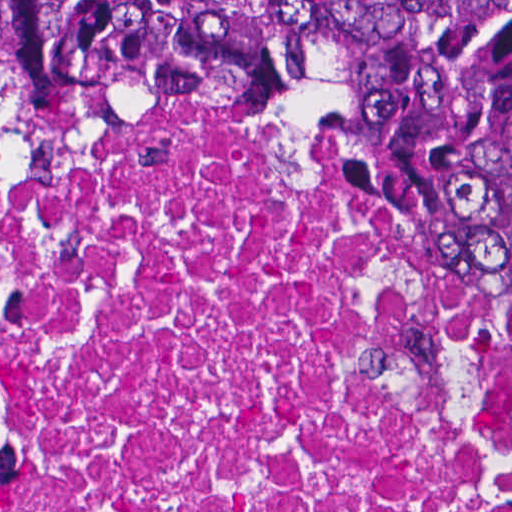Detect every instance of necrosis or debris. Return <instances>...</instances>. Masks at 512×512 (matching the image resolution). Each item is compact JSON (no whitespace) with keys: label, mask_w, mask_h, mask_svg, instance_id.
I'll list each match as a JSON object with an SVG mask.
<instances>
[{"label":"necrosis or debris","mask_w":512,"mask_h":512,"mask_svg":"<svg viewBox=\"0 0 512 512\" xmlns=\"http://www.w3.org/2000/svg\"><path fill=\"white\" fill-rule=\"evenodd\" d=\"M0 512H512V354L327 169L0 100Z\"/></svg>","instance_id":"1"}]
</instances>
